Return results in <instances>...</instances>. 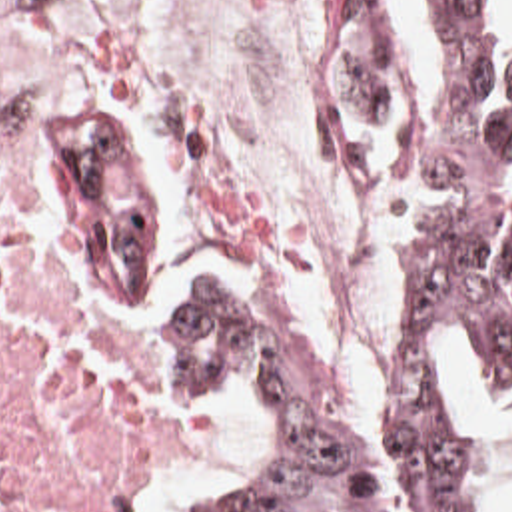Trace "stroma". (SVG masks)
<instances>
[{"label": "stroma", "mask_w": 512, "mask_h": 512, "mask_svg": "<svg viewBox=\"0 0 512 512\" xmlns=\"http://www.w3.org/2000/svg\"><path fill=\"white\" fill-rule=\"evenodd\" d=\"M63 1L69 2L79 10L105 18L123 34H127L131 40H135L139 46H143L147 52H151L159 60V64L169 72V76L177 82V86L183 90L203 132H205V114H211V112L223 114L219 108L211 104V100L201 90V86L195 80H191L179 66H175L161 52L159 44L155 42V38L151 36L143 18L137 12L139 0ZM337 16H385L395 34L397 48L407 68L426 66V62L419 52L415 28L403 0H343L323 20V66L311 88V122H313L315 140L323 150L325 158L329 160L331 168L335 170L339 182L345 188L357 190L363 196H367L375 204V208L383 214V218L389 222L397 238L395 214L385 192L379 190L375 184H371L335 148L325 128V56H327L329 34L333 30ZM23 128H25L23 124L9 120L0 112V164L13 166L15 170H19V150H21ZM65 246L71 256L79 258L91 270L99 272L101 276H105L107 280H111L113 284L121 286L131 294L147 296L149 292L155 290V250L133 236L127 200L123 196L115 170L91 146L75 140H67V138H65ZM395 274H397V264L379 306L377 354H375L373 368L379 362L385 332H387V306L393 294ZM452 354H454V366L458 374V428H456L454 456H452V512H482L486 506L492 480L502 464V448L498 442L480 438L466 430V388H464L466 360L472 368L474 392L480 398L488 402H512V392L486 390L476 368L474 352L452 346ZM311 362H313V370H315V378H317V386L321 390L323 402L331 418L335 420L337 428L357 432V428L363 424L365 418L353 422L351 418L345 416L341 390L315 364L313 356H311ZM165 476L151 480L149 488L145 490L137 506V512L145 502V498L149 496V492Z\"/></svg>", "instance_id": "stroma-1"}]
</instances>
